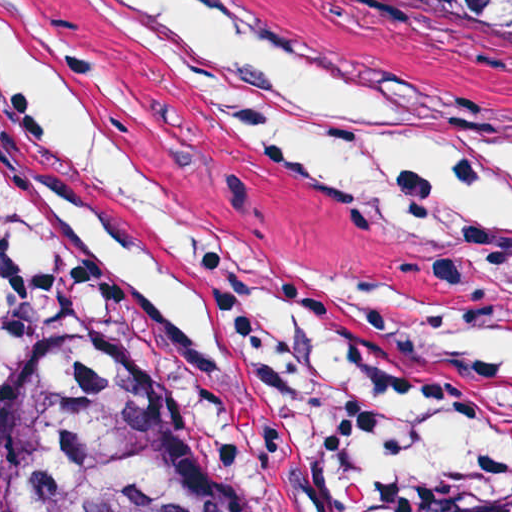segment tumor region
Returning a JSON list of instances; mask_svg holds the SVG:
<instances>
[{
    "label": "tumor region",
    "instance_id": "1",
    "mask_svg": "<svg viewBox=\"0 0 512 512\" xmlns=\"http://www.w3.org/2000/svg\"><path fill=\"white\" fill-rule=\"evenodd\" d=\"M408 1L512 93V0ZM0 512H251V454L185 372L91 344L0 405ZM414 512H512V490L428 494Z\"/></svg>",
    "mask_w": 512,
    "mask_h": 512
}]
</instances>
